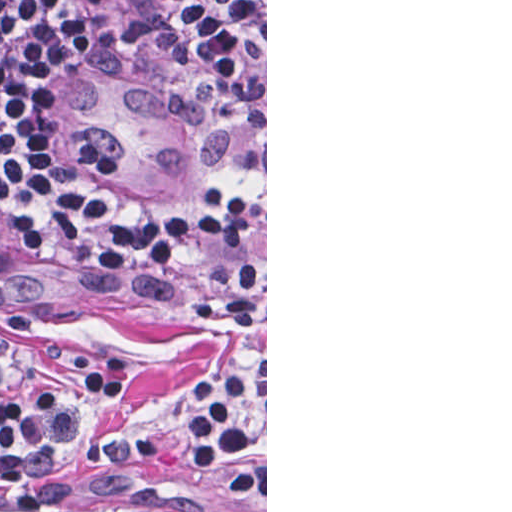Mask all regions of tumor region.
I'll return each mask as SVG.
<instances>
[{
  "label": "tumor region",
  "instance_id": "tumor-region-1",
  "mask_svg": "<svg viewBox=\"0 0 512 512\" xmlns=\"http://www.w3.org/2000/svg\"><path fill=\"white\" fill-rule=\"evenodd\" d=\"M159 1L169 19L230 83L239 101L241 142L234 164L216 174L191 182H158L131 177L121 170L109 158L84 106L58 0H48L51 40L57 57V77L51 101V130L57 142L82 168L103 176L112 184L154 202H187L204 191L185 195L233 169L251 149L260 128V84L216 58L191 24L178 12L173 0Z\"/></svg>",
  "mask_w": 512,
  "mask_h": 512
}]
</instances>
